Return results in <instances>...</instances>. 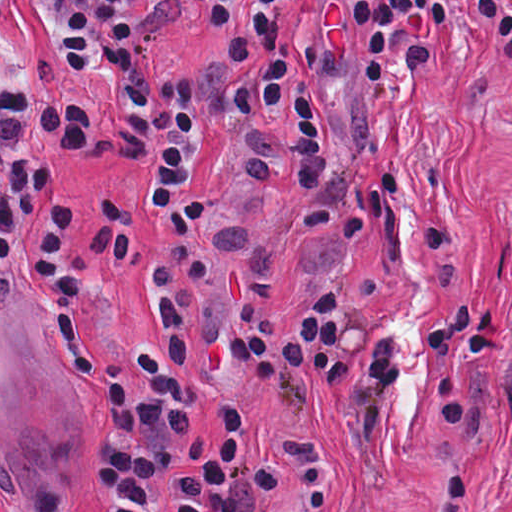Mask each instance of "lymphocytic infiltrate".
<instances>
[{"instance_id": "lymphocytic-infiltrate-1", "label": "lymphocytic infiltrate", "mask_w": 512, "mask_h": 512, "mask_svg": "<svg viewBox=\"0 0 512 512\" xmlns=\"http://www.w3.org/2000/svg\"><path fill=\"white\" fill-rule=\"evenodd\" d=\"M79 72L106 71L125 103L126 124L111 150L129 162L160 214L150 255L157 332L133 351L95 336L86 290L126 256L129 239L106 191L57 213V242L44 281L63 325L67 353L109 407V428L89 468L101 512H258L288 491L302 512H326L346 497L349 461L321 447L264 440L258 421L233 410L207 444L191 426L198 393L191 366L194 297L210 265L204 242L209 199L189 195L200 140L224 129L245 143V172L267 198L299 193L300 223L334 235L388 217L401 196L394 175L346 190L330 179L322 142V93H386L400 77L440 58V29L455 15L512 50V0H189L228 25L226 54L188 73L154 76L137 23L139 0H45ZM10 0H0V21ZM94 117L79 98L33 95L0 69V265L49 201L33 164L43 154L94 143ZM447 219L425 230L426 268L450 254ZM417 324L429 386L445 417L462 424L465 387L482 348L502 342L497 296L449 294ZM264 386L283 384L308 405L352 382L358 439L384 447L389 401L405 379L398 333L358 316L326 287L292 319L251 310L220 331ZM473 475L452 465L432 512H459ZM19 512H50L30 498Z\"/></svg>"}]
</instances>
